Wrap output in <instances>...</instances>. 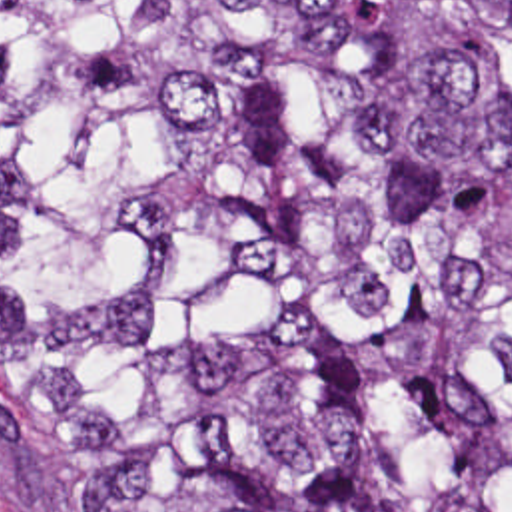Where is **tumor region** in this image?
I'll return each instance as SVG.
<instances>
[{"instance_id":"obj_1","label":"tumor region","mask_w":512,"mask_h":512,"mask_svg":"<svg viewBox=\"0 0 512 512\" xmlns=\"http://www.w3.org/2000/svg\"><path fill=\"white\" fill-rule=\"evenodd\" d=\"M0 401L39 512H512V0H0Z\"/></svg>"}]
</instances>
